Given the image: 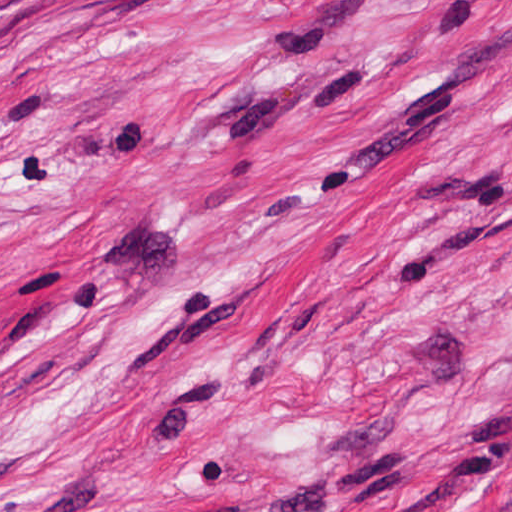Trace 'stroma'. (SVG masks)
<instances>
[{
	"label": "stroma",
	"mask_w": 512,
	"mask_h": 512,
	"mask_svg": "<svg viewBox=\"0 0 512 512\" xmlns=\"http://www.w3.org/2000/svg\"><path fill=\"white\" fill-rule=\"evenodd\" d=\"M0 512H512V0H0Z\"/></svg>",
	"instance_id": "stroma-1"
}]
</instances>
